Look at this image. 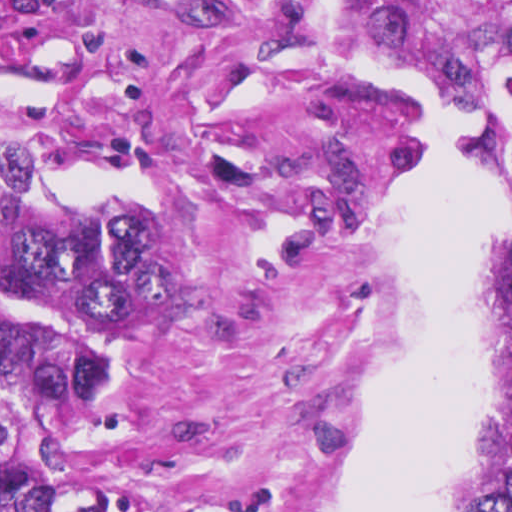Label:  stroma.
<instances>
[{
    "label": "stroma",
    "instance_id": "1",
    "mask_svg": "<svg viewBox=\"0 0 512 512\" xmlns=\"http://www.w3.org/2000/svg\"><path fill=\"white\" fill-rule=\"evenodd\" d=\"M366 65L331 0H0V512L1 225L66 167L137 173L169 236L96 476L199 512H338L407 307L382 239L426 171L420 105L357 87ZM477 168L500 278L502 175L486 147ZM493 386L497 406V337Z\"/></svg>",
    "mask_w": 512,
    "mask_h": 512
}]
</instances>
